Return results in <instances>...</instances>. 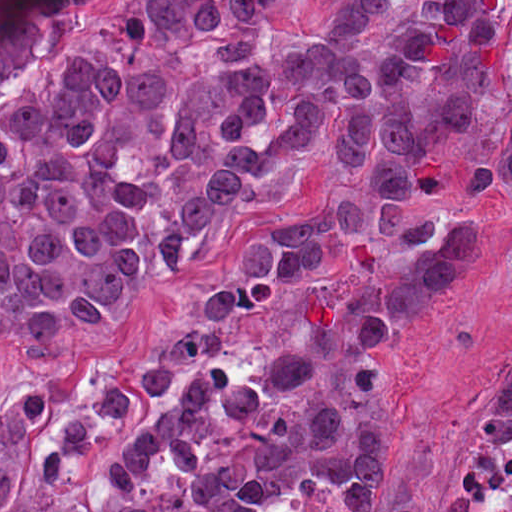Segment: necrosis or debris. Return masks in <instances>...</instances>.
<instances>
[{"label": "necrosis or debris", "mask_w": 512, "mask_h": 512, "mask_svg": "<svg viewBox=\"0 0 512 512\" xmlns=\"http://www.w3.org/2000/svg\"><path fill=\"white\" fill-rule=\"evenodd\" d=\"M457 512H512V422L467 450L455 488Z\"/></svg>", "instance_id": "1"}]
</instances>
